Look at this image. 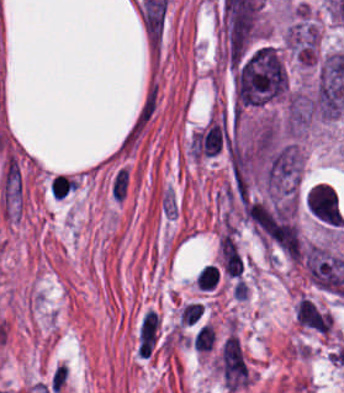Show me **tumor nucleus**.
<instances>
[{"mask_svg": "<svg viewBox=\"0 0 344 393\" xmlns=\"http://www.w3.org/2000/svg\"><path fill=\"white\" fill-rule=\"evenodd\" d=\"M302 170H303V153L299 148L297 191L299 188V182H300Z\"/></svg>", "mask_w": 344, "mask_h": 393, "instance_id": "tumor-nucleus-3", "label": "tumor nucleus"}, {"mask_svg": "<svg viewBox=\"0 0 344 393\" xmlns=\"http://www.w3.org/2000/svg\"><path fill=\"white\" fill-rule=\"evenodd\" d=\"M309 212L321 223L341 227L344 216L338 196L330 184L318 182L309 189L305 199Z\"/></svg>", "mask_w": 344, "mask_h": 393, "instance_id": "tumor-nucleus-1", "label": "tumor nucleus"}, {"mask_svg": "<svg viewBox=\"0 0 344 393\" xmlns=\"http://www.w3.org/2000/svg\"><path fill=\"white\" fill-rule=\"evenodd\" d=\"M294 317L302 328L321 334H329L333 328L330 312L303 296L295 305Z\"/></svg>", "mask_w": 344, "mask_h": 393, "instance_id": "tumor-nucleus-2", "label": "tumor nucleus"}]
</instances>
